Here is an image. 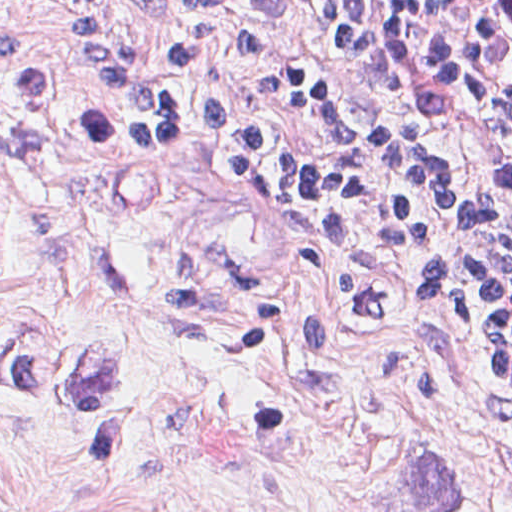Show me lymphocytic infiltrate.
I'll list each match as a JSON object with an SVG mask.
<instances>
[{"label": "lymphocytic infiltrate", "instance_id": "f902f5d3", "mask_svg": "<svg viewBox=\"0 0 512 512\" xmlns=\"http://www.w3.org/2000/svg\"><path fill=\"white\" fill-rule=\"evenodd\" d=\"M273 1L312 64L277 50L229 0L123 3L177 38L169 76L198 72L220 43L257 97L324 136L355 103L368 146L306 150L228 98L175 96L144 75L99 0L62 7L87 57L127 95L131 140L199 154L229 182L274 193L323 254L344 255L365 232L398 264L423 248L428 264L407 291L512 392V265L442 223L512 259V0Z\"/></svg>", "mask_w": 512, "mask_h": 512}]
</instances>
